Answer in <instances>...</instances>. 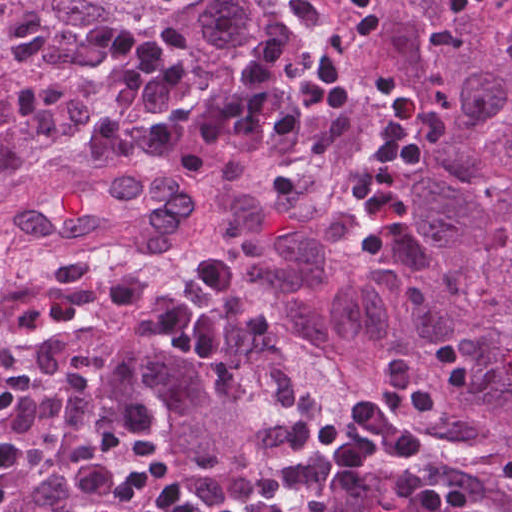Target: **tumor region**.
I'll use <instances>...</instances> for the list:
<instances>
[{
	"mask_svg": "<svg viewBox=\"0 0 512 512\" xmlns=\"http://www.w3.org/2000/svg\"><path fill=\"white\" fill-rule=\"evenodd\" d=\"M351 0H0V179L296 445L374 389L390 356L447 403L423 456L473 512H512V14L373 0L382 24L355 98L293 144L189 180L150 160L101 180L81 124L115 89L86 46L99 18L156 29L191 76L187 106L231 95L262 43L289 84ZM416 139L399 225L353 213L379 132ZM370 512H408L397 461L322 468Z\"/></svg>",
	"mask_w": 512,
	"mask_h": 512,
	"instance_id": "tumor-region-1",
	"label": "tumor region"
}]
</instances>
